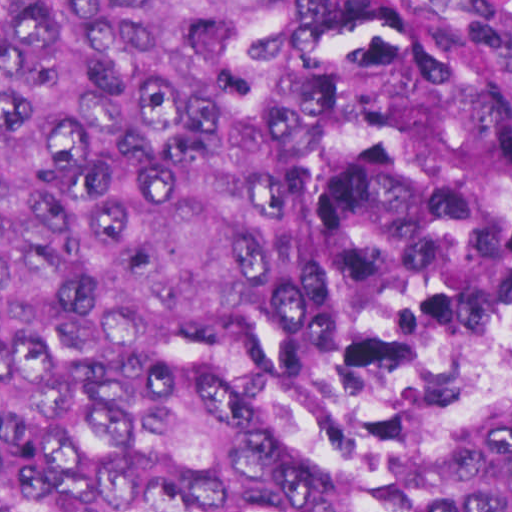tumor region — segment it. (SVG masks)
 <instances>
[{
  "mask_svg": "<svg viewBox=\"0 0 512 512\" xmlns=\"http://www.w3.org/2000/svg\"><path fill=\"white\" fill-rule=\"evenodd\" d=\"M0 512H512V53L0 0Z\"/></svg>",
  "mask_w": 512,
  "mask_h": 512,
  "instance_id": "tumor-region-1",
  "label": "tumor region"
}]
</instances>
